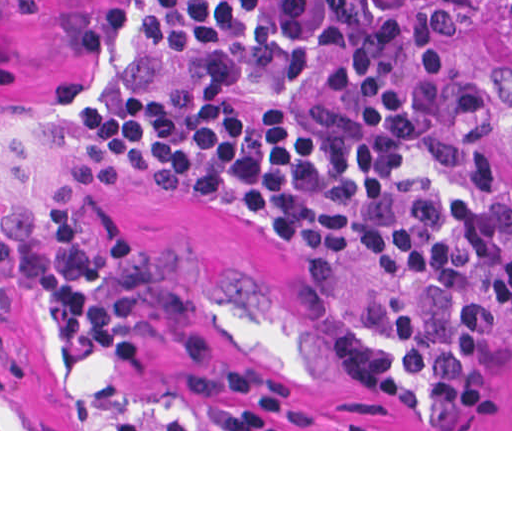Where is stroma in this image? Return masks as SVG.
Wrapping results in <instances>:
<instances>
[{
    "label": "stroma",
    "mask_w": 512,
    "mask_h": 512,
    "mask_svg": "<svg viewBox=\"0 0 512 512\" xmlns=\"http://www.w3.org/2000/svg\"><path fill=\"white\" fill-rule=\"evenodd\" d=\"M420 1L488 85L512 242V0ZM149 3L0 0V214L30 205L48 232L67 207L91 243L147 246L194 294L219 358L208 367L155 340L140 369L68 354L51 299L33 295L4 329L25 366L0 388V431H512V324L484 394L443 429L406 283L352 262L318 294L303 262L230 199L101 172L83 112L125 64Z\"/></svg>",
    "instance_id": "35a3bbf8"
}]
</instances>
